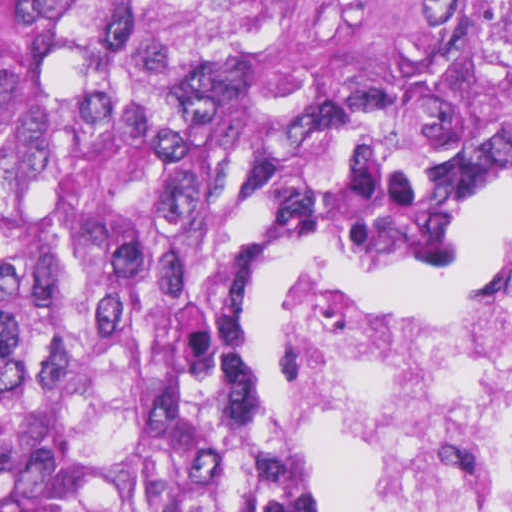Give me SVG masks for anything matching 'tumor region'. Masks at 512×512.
I'll return each instance as SVG.
<instances>
[{
    "label": "tumor region",
    "mask_w": 512,
    "mask_h": 512,
    "mask_svg": "<svg viewBox=\"0 0 512 512\" xmlns=\"http://www.w3.org/2000/svg\"><path fill=\"white\" fill-rule=\"evenodd\" d=\"M504 127L512 0H0V512H305L238 323Z\"/></svg>",
    "instance_id": "1"
}]
</instances>
